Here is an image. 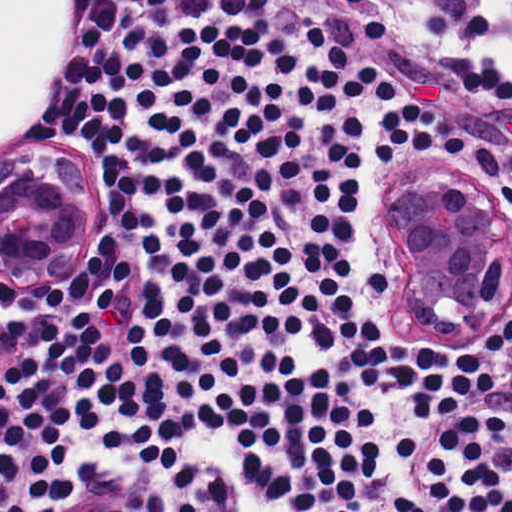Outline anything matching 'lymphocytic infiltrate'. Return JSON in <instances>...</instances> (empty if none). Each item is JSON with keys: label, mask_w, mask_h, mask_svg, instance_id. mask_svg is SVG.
Instances as JSON below:
<instances>
[{"label": "lymphocytic infiltrate", "mask_w": 512, "mask_h": 512, "mask_svg": "<svg viewBox=\"0 0 512 512\" xmlns=\"http://www.w3.org/2000/svg\"><path fill=\"white\" fill-rule=\"evenodd\" d=\"M63 9L57 141L1 160L78 162L95 218L1 263L0 512H512V317L406 333L380 222L444 152L512 201V143L422 100L376 145L395 82L273 0Z\"/></svg>", "instance_id": "f902f5d3"}]
</instances>
